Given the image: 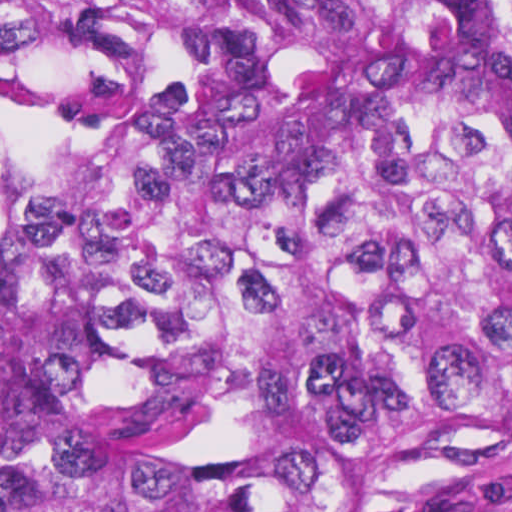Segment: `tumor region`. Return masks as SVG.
Returning a JSON list of instances; mask_svg holds the SVG:
<instances>
[{"mask_svg": "<svg viewBox=\"0 0 512 512\" xmlns=\"http://www.w3.org/2000/svg\"><path fill=\"white\" fill-rule=\"evenodd\" d=\"M105 57L0 139V512H380L512 450V0H0Z\"/></svg>", "mask_w": 512, "mask_h": 512, "instance_id": "e687c5a6", "label": "tumor region"}]
</instances>
